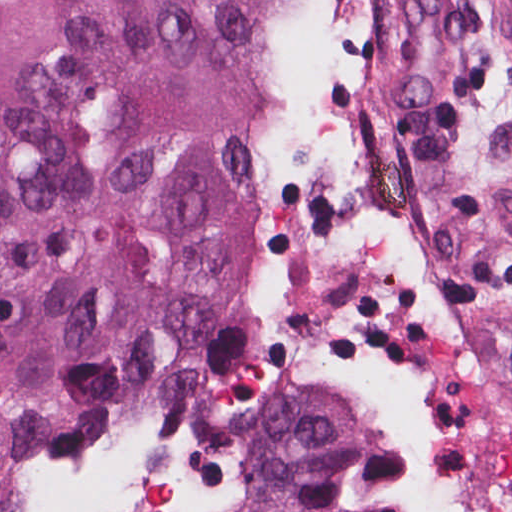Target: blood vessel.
Here are the masks:
<instances>
[{
    "instance_id": "1",
    "label": "blood vessel",
    "mask_w": 512,
    "mask_h": 512,
    "mask_svg": "<svg viewBox=\"0 0 512 512\" xmlns=\"http://www.w3.org/2000/svg\"><path fill=\"white\" fill-rule=\"evenodd\" d=\"M367 2L375 78L392 110L412 112L456 61L463 39L459 9L455 0Z\"/></svg>"
}]
</instances>
